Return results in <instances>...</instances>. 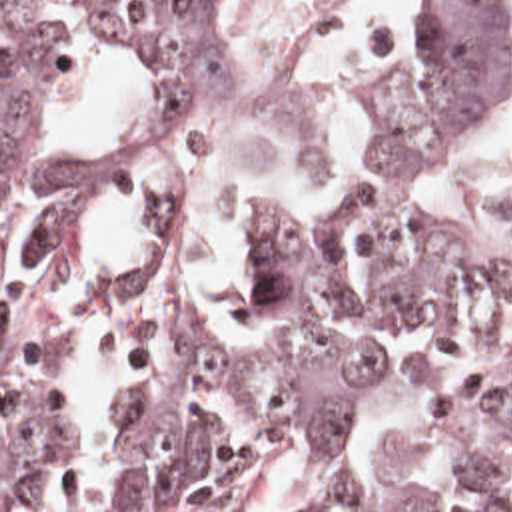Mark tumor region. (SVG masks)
<instances>
[{"label": "tumor region", "instance_id": "e687c5a6", "mask_svg": "<svg viewBox=\"0 0 512 512\" xmlns=\"http://www.w3.org/2000/svg\"><path fill=\"white\" fill-rule=\"evenodd\" d=\"M144 94L116 152L54 148L18 0H0V512H36L84 450L56 294L102 192L146 244L102 302L130 398L108 434L104 505L244 512L274 444L300 434L316 479L294 512H512V236L404 212L406 188L465 146L512 84V0H436V38L382 86L326 220L256 236V334L206 330L178 250V202L236 80L252 0H96ZM512 232V188L493 198Z\"/></svg>", "mask_w": 512, "mask_h": 512}]
</instances>
